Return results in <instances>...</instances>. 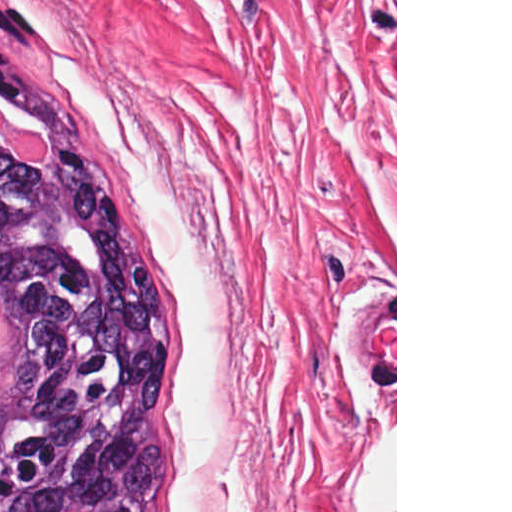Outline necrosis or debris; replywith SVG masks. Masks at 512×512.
Segmentation results:
<instances>
[{
  "mask_svg": "<svg viewBox=\"0 0 512 512\" xmlns=\"http://www.w3.org/2000/svg\"><path fill=\"white\" fill-rule=\"evenodd\" d=\"M0 141L7 150L13 151L24 162L46 159L48 148L41 135L10 116L7 108L3 106H0Z\"/></svg>",
  "mask_w": 512,
  "mask_h": 512,
  "instance_id": "1",
  "label": "necrosis or debris"
}]
</instances>
